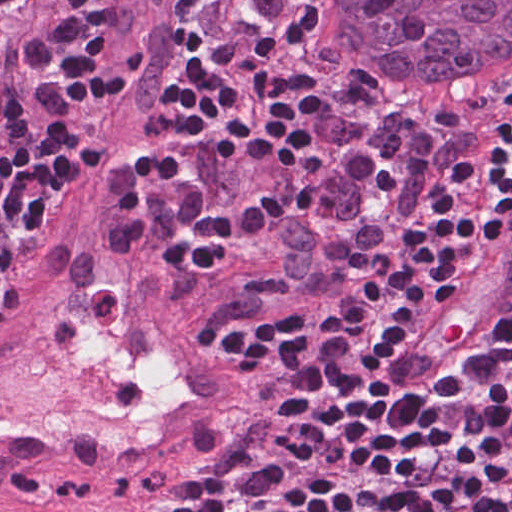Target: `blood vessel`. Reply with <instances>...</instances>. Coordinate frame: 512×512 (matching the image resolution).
I'll use <instances>...</instances> for the list:
<instances>
[{"label": "blood vessel", "instance_id": "8fb6f2fc", "mask_svg": "<svg viewBox=\"0 0 512 512\" xmlns=\"http://www.w3.org/2000/svg\"><path fill=\"white\" fill-rule=\"evenodd\" d=\"M181 5L127 0V61L97 126L119 149L162 116ZM147 176L126 161L73 178L0 295V491L108 477L251 417L204 290L170 288ZM470 257L383 359L402 404L432 402L512 309V225Z\"/></svg>", "mask_w": 512, "mask_h": 512}]
</instances>
